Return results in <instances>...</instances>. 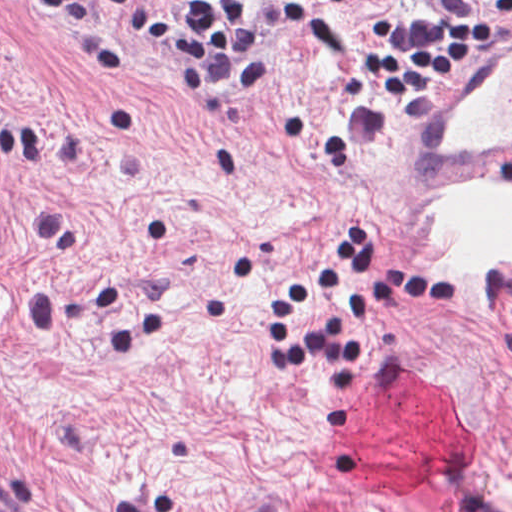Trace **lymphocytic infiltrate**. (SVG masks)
I'll return each instance as SVG.
<instances>
[{"label":"lymphocytic infiltrate","instance_id":"lymphocytic-infiltrate-1","mask_svg":"<svg viewBox=\"0 0 512 512\" xmlns=\"http://www.w3.org/2000/svg\"><path fill=\"white\" fill-rule=\"evenodd\" d=\"M319 6L353 0H309ZM512 13V0H488ZM271 0H0V7L43 11L84 36L115 16L155 54L171 58L188 108L202 120H221L229 105L258 95L270 82L268 19ZM409 34L391 22L374 23V43L362 66L366 78H352L347 102L381 101L415 92L431 94L438 80L452 76L457 61L470 58L495 34L481 19L435 21L410 17ZM512 187V160L500 171ZM381 241L367 225L344 231L326 263L302 270L281 284L266 305L272 369H300L337 362L357 365L366 350L345 332L356 315L401 306L409 298L440 301L459 295L463 281L429 272L391 268L383 285L351 297L311 332L298 334L299 309L341 286L363 285L378 276Z\"/></svg>","mask_w":512,"mask_h":512}]
</instances>
